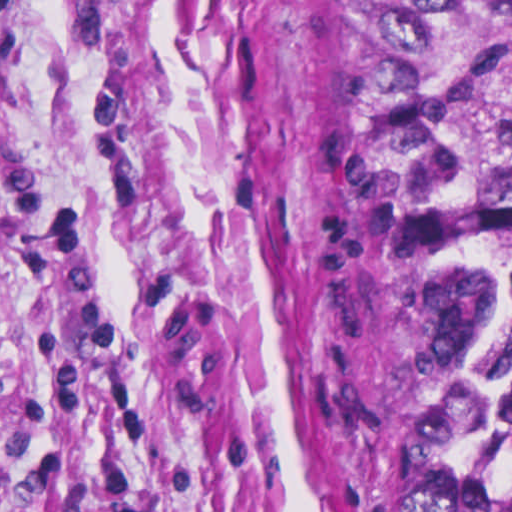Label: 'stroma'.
I'll list each match as a JSON object with an SVG mask.
<instances>
[{
	"label": "stroma",
	"instance_id": "35a3bbf8",
	"mask_svg": "<svg viewBox=\"0 0 512 512\" xmlns=\"http://www.w3.org/2000/svg\"><path fill=\"white\" fill-rule=\"evenodd\" d=\"M379 0H0V512H397Z\"/></svg>",
	"mask_w": 512,
	"mask_h": 512
}]
</instances>
